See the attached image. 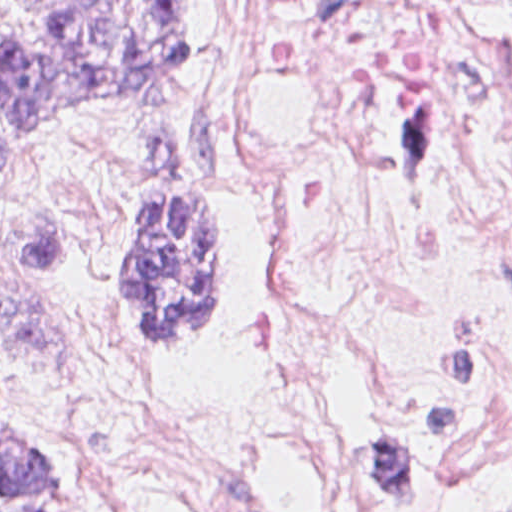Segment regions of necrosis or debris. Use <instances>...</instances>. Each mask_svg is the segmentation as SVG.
I'll use <instances>...</instances> for the list:
<instances>
[{"label":"necrosis or debris","mask_w":512,"mask_h":512,"mask_svg":"<svg viewBox=\"0 0 512 512\" xmlns=\"http://www.w3.org/2000/svg\"><path fill=\"white\" fill-rule=\"evenodd\" d=\"M257 266L220 338L109 342L89 395L147 512L324 477L512 512V54L452 0H219Z\"/></svg>","instance_id":"obj_1"}]
</instances>
